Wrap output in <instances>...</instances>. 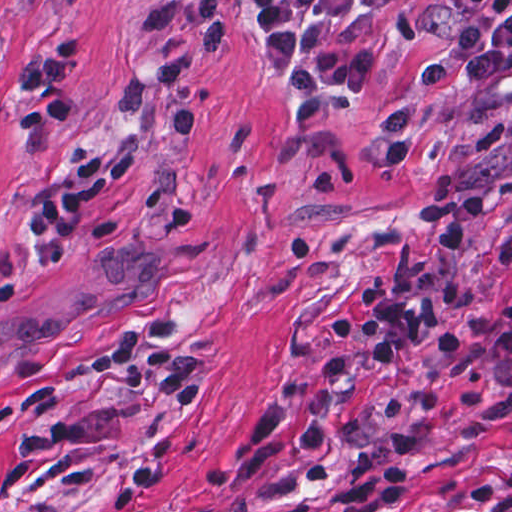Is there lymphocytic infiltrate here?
<instances>
[{"label":"lymphocytic infiltrate","instance_id":"f902f5d3","mask_svg":"<svg viewBox=\"0 0 512 512\" xmlns=\"http://www.w3.org/2000/svg\"><path fill=\"white\" fill-rule=\"evenodd\" d=\"M254 39L275 61L278 78L292 92L301 120L339 112L348 96L308 52L319 28L348 15H378L415 0H247ZM460 28L451 42L420 65L395 89L384 105L376 145L387 168H407L420 145L413 131L412 109L402 96L406 87L432 89L448 83L474 47L489 37L510 0H454ZM108 170L106 155L87 157L66 184L33 212L34 263L45 273H59L75 260L80 234L89 215L90 193ZM486 210L462 196L416 218L414 227L430 239L428 266L420 271L383 277L359 285V302L330 324L333 341L354 345L347 364L328 366L324 378L348 386L413 355L429 337L447 354L483 347L512 354V295L493 325H451L439 331L447 315V290L469 263L471 247ZM502 401L512 410V383ZM417 432L396 427L362 447L342 466L326 502L312 512H393L408 496L407 476Z\"/></svg>","mask_w":512,"mask_h":512}]
</instances>
